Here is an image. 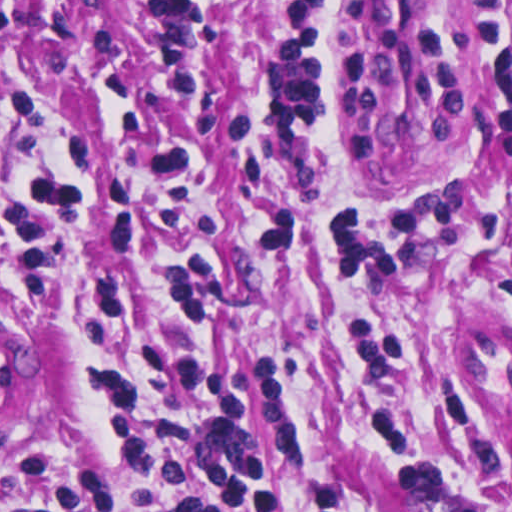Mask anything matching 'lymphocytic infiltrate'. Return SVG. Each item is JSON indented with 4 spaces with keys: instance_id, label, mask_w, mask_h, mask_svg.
Masks as SVG:
<instances>
[{
    "instance_id": "f902f5d3",
    "label": "lymphocytic infiltrate",
    "mask_w": 512,
    "mask_h": 512,
    "mask_svg": "<svg viewBox=\"0 0 512 512\" xmlns=\"http://www.w3.org/2000/svg\"><path fill=\"white\" fill-rule=\"evenodd\" d=\"M69 81L91 85L92 114L12 196V239L26 299H60L68 290L72 241L95 200L96 148L124 93L50 63L0 65V145L38 129L46 88ZM128 119L136 130H159L174 120L135 95ZM215 166L213 147L201 137L171 155L125 164L105 243L113 252H133L150 236L186 240L183 222L204 174ZM255 200L250 219L289 216L267 200ZM246 234L269 300L274 265L268 244L250 221ZM156 301H167L173 323L214 316L218 291L212 256L188 245L160 279H102L87 315L88 332L112 334L140 307ZM103 399L128 470L186 491V501L167 512H272L282 472L272 424L275 476L255 453L245 402L226 372L173 336L171 328L156 344L106 372ZM0 512H114V492L87 467L66 463L50 470L30 457L0 479Z\"/></svg>"
}]
</instances>
